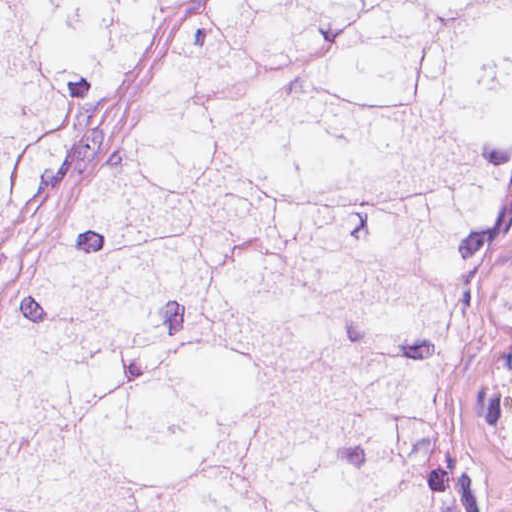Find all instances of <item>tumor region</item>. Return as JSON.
I'll return each instance as SVG.
<instances>
[{
  "label": "tumor region",
  "mask_w": 512,
  "mask_h": 512,
  "mask_svg": "<svg viewBox=\"0 0 512 512\" xmlns=\"http://www.w3.org/2000/svg\"><path fill=\"white\" fill-rule=\"evenodd\" d=\"M200 1H0V219ZM512 1H226L0 326V512H512Z\"/></svg>",
  "instance_id": "obj_1"
}]
</instances>
